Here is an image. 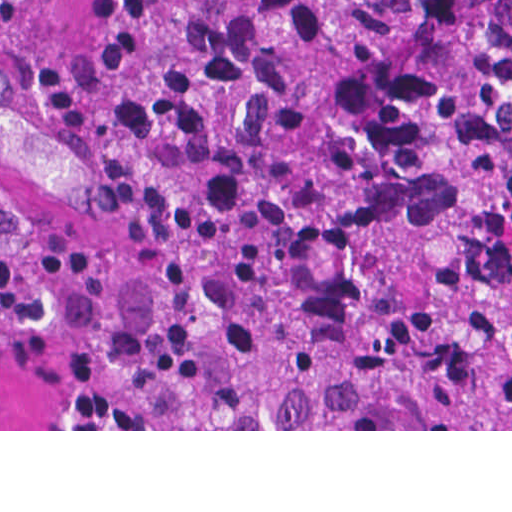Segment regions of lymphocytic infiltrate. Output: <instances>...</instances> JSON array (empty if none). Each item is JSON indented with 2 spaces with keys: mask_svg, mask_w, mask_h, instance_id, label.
<instances>
[{
  "mask_svg": "<svg viewBox=\"0 0 512 512\" xmlns=\"http://www.w3.org/2000/svg\"><path fill=\"white\" fill-rule=\"evenodd\" d=\"M43 311L0 244V324L34 322Z\"/></svg>",
  "mask_w": 512,
  "mask_h": 512,
  "instance_id": "obj_1",
  "label": "lymphocytic infiltrate"
}]
</instances>
